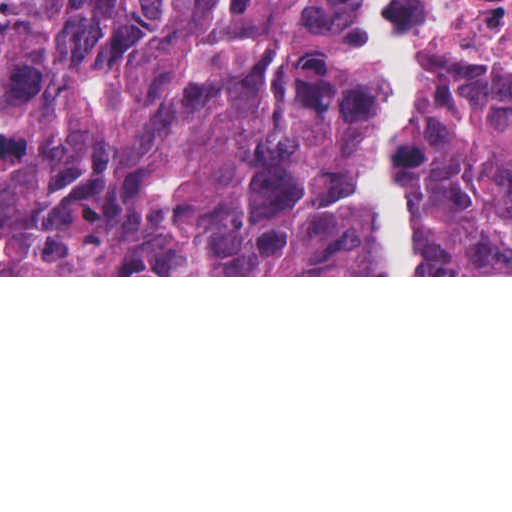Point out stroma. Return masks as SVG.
Instances as JSON below:
<instances>
[{"label":"stroma","instance_id":"obj_1","mask_svg":"<svg viewBox=\"0 0 512 512\" xmlns=\"http://www.w3.org/2000/svg\"><path fill=\"white\" fill-rule=\"evenodd\" d=\"M418 39V130L422 98L440 72L489 63L512 67L511 38H479L462 20L456 0H429V7L399 15ZM377 88L367 56L350 103L349 137L371 138ZM418 133L410 165V194L415 226L423 178ZM366 184L358 203L357 232ZM0 275V277H512V275Z\"/></svg>","mask_w":512,"mask_h":512}]
</instances>
